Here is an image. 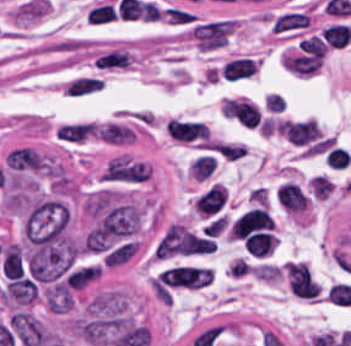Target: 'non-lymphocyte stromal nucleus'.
<instances>
[{"instance_id":"1","label":"non-lymphocyte stromal nucleus","mask_w":351,"mask_h":346,"mask_svg":"<svg viewBox=\"0 0 351 346\" xmlns=\"http://www.w3.org/2000/svg\"><path fill=\"white\" fill-rule=\"evenodd\" d=\"M102 77L95 74H76L61 84L63 95L69 99H83L100 91Z\"/></svg>"},{"instance_id":"2","label":"non-lymphocyte stromal nucleus","mask_w":351,"mask_h":346,"mask_svg":"<svg viewBox=\"0 0 351 346\" xmlns=\"http://www.w3.org/2000/svg\"><path fill=\"white\" fill-rule=\"evenodd\" d=\"M130 57L124 50H110L93 60L99 69L129 67Z\"/></svg>"}]
</instances>
